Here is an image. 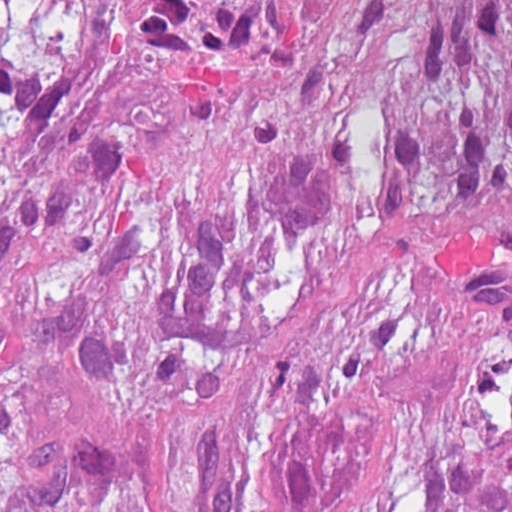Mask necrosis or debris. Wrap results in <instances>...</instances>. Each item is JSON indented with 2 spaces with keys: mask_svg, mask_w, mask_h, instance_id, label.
<instances>
[{
  "mask_svg": "<svg viewBox=\"0 0 512 512\" xmlns=\"http://www.w3.org/2000/svg\"><path fill=\"white\" fill-rule=\"evenodd\" d=\"M144 0H0V19L138 9ZM158 3H512V0H146Z\"/></svg>",
  "mask_w": 512,
  "mask_h": 512,
  "instance_id": "4bbe7bcc",
  "label": "necrosis or debris"
}]
</instances>
